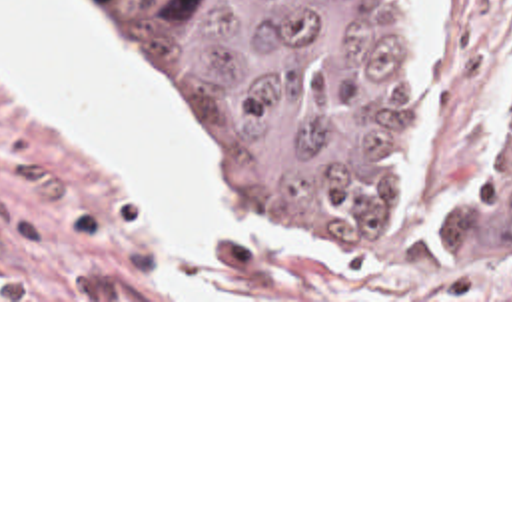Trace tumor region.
I'll return each instance as SVG.
<instances>
[{
    "label": "tumor region",
    "mask_w": 512,
    "mask_h": 512,
    "mask_svg": "<svg viewBox=\"0 0 512 512\" xmlns=\"http://www.w3.org/2000/svg\"><path fill=\"white\" fill-rule=\"evenodd\" d=\"M200 180L263 256H433L512 284V126L449 196L403 202L421 116L389 0H98ZM419 208H431L421 212Z\"/></svg>",
    "instance_id": "obj_1"
}]
</instances>
